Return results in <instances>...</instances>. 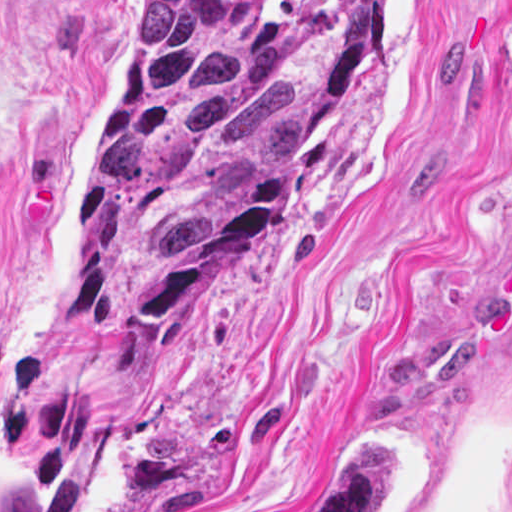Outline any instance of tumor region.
<instances>
[{
    "label": "tumor region",
    "instance_id": "1",
    "mask_svg": "<svg viewBox=\"0 0 512 512\" xmlns=\"http://www.w3.org/2000/svg\"><path fill=\"white\" fill-rule=\"evenodd\" d=\"M387 0H150L92 119L79 308L155 357L318 163ZM391 449L332 445L301 512H388Z\"/></svg>",
    "mask_w": 512,
    "mask_h": 512
}]
</instances>
